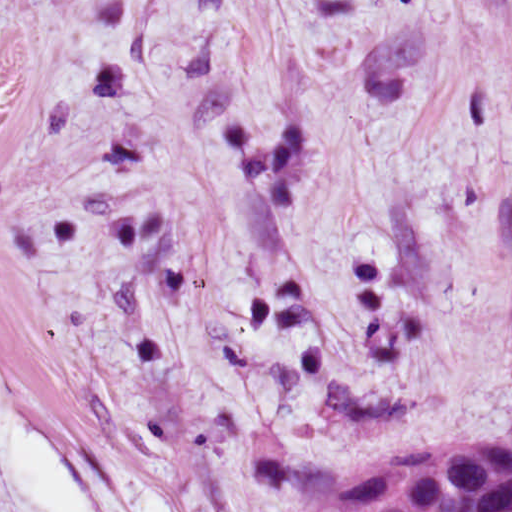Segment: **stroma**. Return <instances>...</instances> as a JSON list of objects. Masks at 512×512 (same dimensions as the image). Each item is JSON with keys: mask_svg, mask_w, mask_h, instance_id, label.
<instances>
[{"mask_svg": "<svg viewBox=\"0 0 512 512\" xmlns=\"http://www.w3.org/2000/svg\"><path fill=\"white\" fill-rule=\"evenodd\" d=\"M0 376L170 512L512 438L507 0H0Z\"/></svg>", "mask_w": 512, "mask_h": 512, "instance_id": "obj_1", "label": "stroma"}]
</instances>
